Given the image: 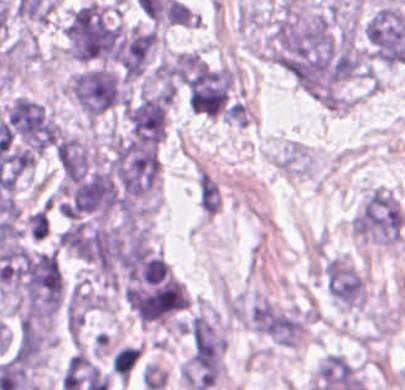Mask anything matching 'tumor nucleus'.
<instances>
[{"mask_svg": "<svg viewBox=\"0 0 405 390\" xmlns=\"http://www.w3.org/2000/svg\"><path fill=\"white\" fill-rule=\"evenodd\" d=\"M270 54L297 83L329 84L339 79L333 34L325 12L281 7L270 33Z\"/></svg>", "mask_w": 405, "mask_h": 390, "instance_id": "obj_1", "label": "tumor nucleus"}, {"mask_svg": "<svg viewBox=\"0 0 405 390\" xmlns=\"http://www.w3.org/2000/svg\"><path fill=\"white\" fill-rule=\"evenodd\" d=\"M120 290L142 321L174 317L185 306L186 290L147 233L131 232L120 259Z\"/></svg>", "mask_w": 405, "mask_h": 390, "instance_id": "obj_2", "label": "tumor nucleus"}, {"mask_svg": "<svg viewBox=\"0 0 405 390\" xmlns=\"http://www.w3.org/2000/svg\"><path fill=\"white\" fill-rule=\"evenodd\" d=\"M1 286L21 318H50L64 289L56 252L18 247L1 266Z\"/></svg>", "mask_w": 405, "mask_h": 390, "instance_id": "obj_3", "label": "tumor nucleus"}, {"mask_svg": "<svg viewBox=\"0 0 405 390\" xmlns=\"http://www.w3.org/2000/svg\"><path fill=\"white\" fill-rule=\"evenodd\" d=\"M66 52L79 60H117L118 26L106 5L86 1L64 23Z\"/></svg>", "mask_w": 405, "mask_h": 390, "instance_id": "obj_4", "label": "tumor nucleus"}, {"mask_svg": "<svg viewBox=\"0 0 405 390\" xmlns=\"http://www.w3.org/2000/svg\"><path fill=\"white\" fill-rule=\"evenodd\" d=\"M68 89L83 113L97 119L124 103L122 75L110 68H84L68 81Z\"/></svg>", "mask_w": 405, "mask_h": 390, "instance_id": "obj_5", "label": "tumor nucleus"}, {"mask_svg": "<svg viewBox=\"0 0 405 390\" xmlns=\"http://www.w3.org/2000/svg\"><path fill=\"white\" fill-rule=\"evenodd\" d=\"M171 103L170 88L147 90L128 101L123 110L130 141L158 145L167 132Z\"/></svg>", "mask_w": 405, "mask_h": 390, "instance_id": "obj_6", "label": "tumor nucleus"}, {"mask_svg": "<svg viewBox=\"0 0 405 390\" xmlns=\"http://www.w3.org/2000/svg\"><path fill=\"white\" fill-rule=\"evenodd\" d=\"M324 273L327 290L334 301L350 307L360 305L364 279L353 264L331 257L326 261Z\"/></svg>", "mask_w": 405, "mask_h": 390, "instance_id": "obj_7", "label": "tumor nucleus"}]
</instances>
